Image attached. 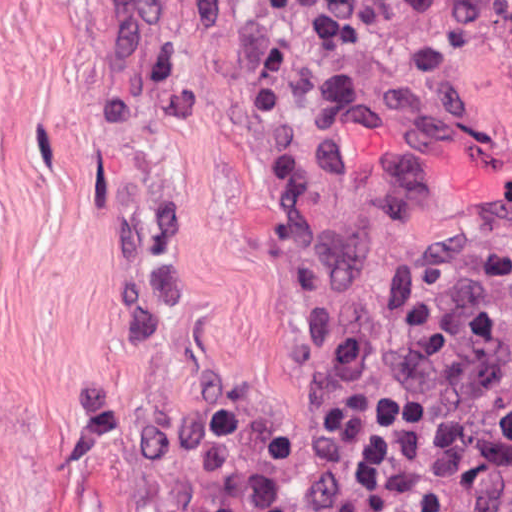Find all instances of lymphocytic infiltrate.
<instances>
[{"mask_svg":"<svg viewBox=\"0 0 512 512\" xmlns=\"http://www.w3.org/2000/svg\"><path fill=\"white\" fill-rule=\"evenodd\" d=\"M511 435L507 215L405 261L311 380L299 468L270 431L172 512H466Z\"/></svg>","mask_w":512,"mask_h":512,"instance_id":"obj_1","label":"lymphocytic infiltrate"}]
</instances>
